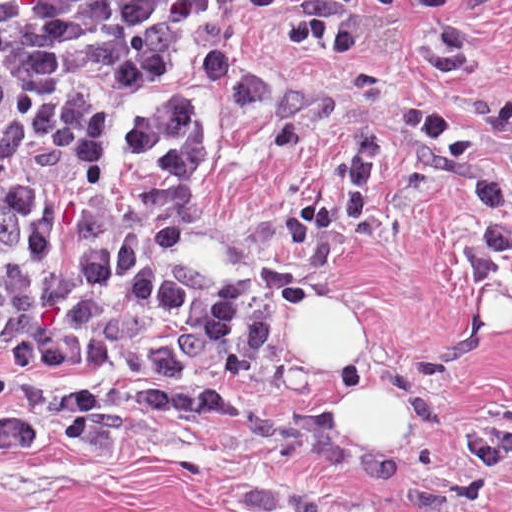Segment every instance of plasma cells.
I'll use <instances>...</instances> for the list:
<instances>
[{"label":"plasma cells","mask_w":512,"mask_h":512,"mask_svg":"<svg viewBox=\"0 0 512 512\" xmlns=\"http://www.w3.org/2000/svg\"><path fill=\"white\" fill-rule=\"evenodd\" d=\"M232 1H0V369H164L227 384L251 350V295L188 250L175 202L209 158L200 89L256 114L277 147L333 111L330 89L282 80L216 40ZM367 0H292L277 44L345 57ZM396 125L449 155L480 208L470 280L512 259V194L485 149L419 107ZM378 142L359 133L318 205L287 217L289 246L259 262L272 291L311 302L364 229ZM431 484L483 505L512 463V410L464 434Z\"/></svg>","instance_id":"plasma-cells-1"}]
</instances>
